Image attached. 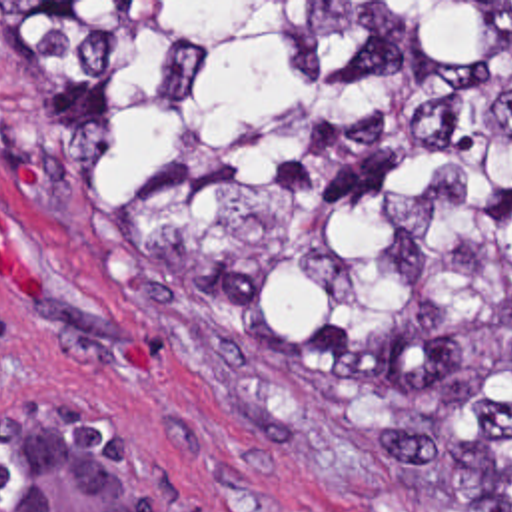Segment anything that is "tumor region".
Wrapping results in <instances>:
<instances>
[{
	"mask_svg": "<svg viewBox=\"0 0 512 512\" xmlns=\"http://www.w3.org/2000/svg\"><path fill=\"white\" fill-rule=\"evenodd\" d=\"M104 216L384 487L512 479V2H0Z\"/></svg>",
	"mask_w": 512,
	"mask_h": 512,
	"instance_id": "1",
	"label": "tumor region"
}]
</instances>
